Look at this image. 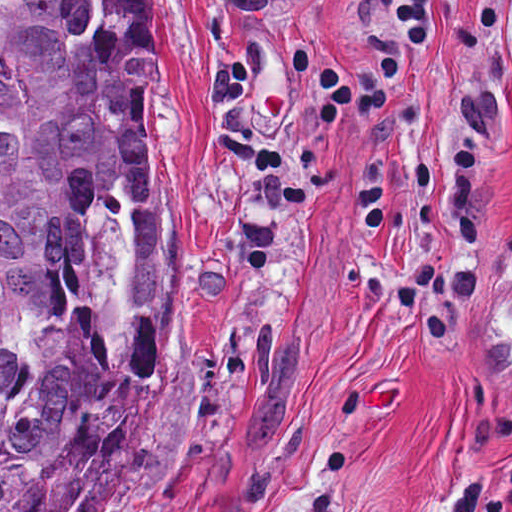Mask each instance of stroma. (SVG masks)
<instances>
[{"label": "stroma", "mask_w": 512, "mask_h": 512, "mask_svg": "<svg viewBox=\"0 0 512 512\" xmlns=\"http://www.w3.org/2000/svg\"><path fill=\"white\" fill-rule=\"evenodd\" d=\"M172 383L104 512H512L500 0H146Z\"/></svg>", "instance_id": "stroma-1"}]
</instances>
